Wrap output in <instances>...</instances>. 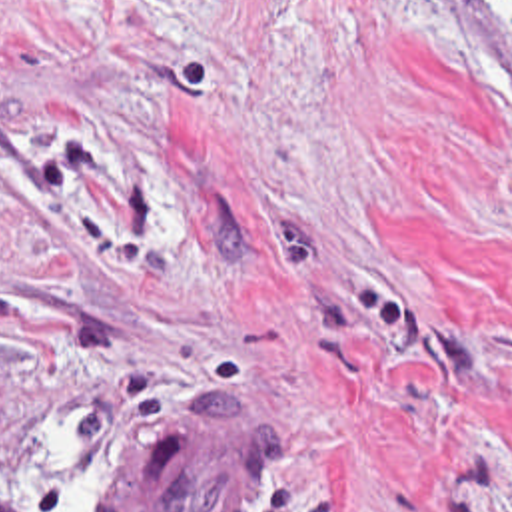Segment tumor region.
<instances>
[{"mask_svg":"<svg viewBox=\"0 0 512 512\" xmlns=\"http://www.w3.org/2000/svg\"><path fill=\"white\" fill-rule=\"evenodd\" d=\"M278 465V412L260 398H199L125 459L105 512H252Z\"/></svg>","mask_w":512,"mask_h":512,"instance_id":"1","label":"tumor region"}]
</instances>
